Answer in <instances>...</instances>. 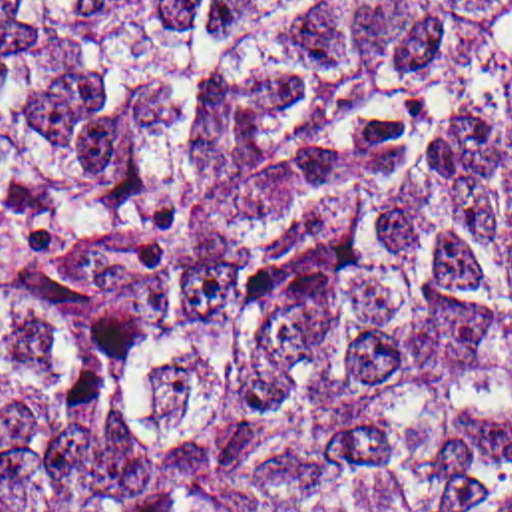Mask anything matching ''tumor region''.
<instances>
[{
	"label": "tumor region",
	"instance_id": "tumor-region-1",
	"mask_svg": "<svg viewBox=\"0 0 512 512\" xmlns=\"http://www.w3.org/2000/svg\"><path fill=\"white\" fill-rule=\"evenodd\" d=\"M0 512H512V0H0Z\"/></svg>",
	"mask_w": 512,
	"mask_h": 512
}]
</instances>
